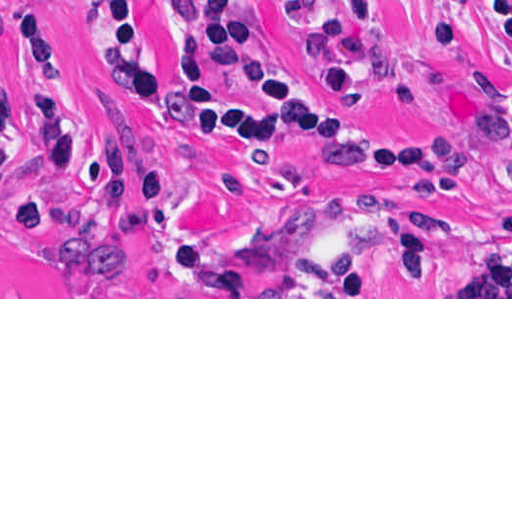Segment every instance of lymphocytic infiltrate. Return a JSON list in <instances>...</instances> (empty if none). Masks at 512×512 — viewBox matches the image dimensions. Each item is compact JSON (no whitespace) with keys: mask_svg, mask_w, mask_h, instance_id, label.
<instances>
[{"mask_svg":"<svg viewBox=\"0 0 512 512\" xmlns=\"http://www.w3.org/2000/svg\"><path fill=\"white\" fill-rule=\"evenodd\" d=\"M74 1L83 5L114 78L172 129L208 147L237 153H258L274 144H317L338 157L419 178L438 176L434 162L366 128L353 96L369 82L399 108L410 110L451 85L447 58L472 23L487 20L512 41V0H439V25L421 65L408 75L387 79L390 52L380 0H356L357 12L349 21L327 20L315 0H279L294 34L331 84L333 94H323L264 43L245 0L179 1L193 64L177 79L156 63L139 0ZM17 76L28 101L61 122L54 147L33 161L46 172L63 173L79 152L81 124L63 91L50 16L41 0H20ZM489 128L512 144V108L492 111ZM23 166L14 170L18 233L41 216V202L28 189ZM169 195V172L153 148L123 137L104 141L93 165L87 256L75 271L52 276L81 279L113 269V255L123 238ZM384 239L386 260L397 276L387 290H429L437 245L412 216L375 199L362 204L348 232L335 290L358 279L370 243ZM151 270L166 293H255L225 257L194 241L167 249ZM481 271L512 273V216L465 263L452 288Z\"/></svg>","mask_w":512,"mask_h":512,"instance_id":"f902f5d3","label":"lymphocytic infiltrate"}]
</instances>
